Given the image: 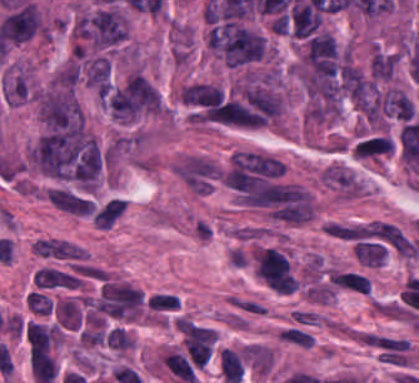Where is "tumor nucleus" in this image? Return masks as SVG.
Returning <instances> with one entry per match:
<instances>
[{"label":"tumor nucleus","mask_w":419,"mask_h":383,"mask_svg":"<svg viewBox=\"0 0 419 383\" xmlns=\"http://www.w3.org/2000/svg\"><path fill=\"white\" fill-rule=\"evenodd\" d=\"M179 98L186 104L210 107L223 102V93L218 87L197 83L182 90Z\"/></svg>","instance_id":"obj_2"},{"label":"tumor nucleus","mask_w":419,"mask_h":383,"mask_svg":"<svg viewBox=\"0 0 419 383\" xmlns=\"http://www.w3.org/2000/svg\"><path fill=\"white\" fill-rule=\"evenodd\" d=\"M87 87L105 93L110 87V65L104 57L90 59L87 69Z\"/></svg>","instance_id":"obj_3"},{"label":"tumor nucleus","mask_w":419,"mask_h":383,"mask_svg":"<svg viewBox=\"0 0 419 383\" xmlns=\"http://www.w3.org/2000/svg\"><path fill=\"white\" fill-rule=\"evenodd\" d=\"M211 45L226 64L234 67L262 57L264 38L253 29L224 22L214 27Z\"/></svg>","instance_id":"obj_1"}]
</instances>
